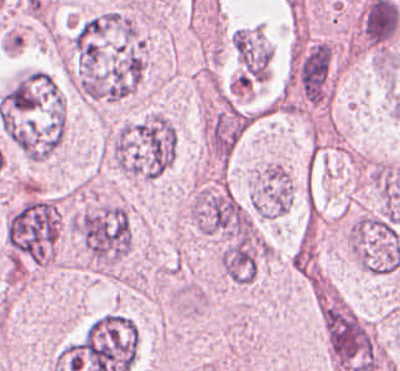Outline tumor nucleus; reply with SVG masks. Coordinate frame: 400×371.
Instances as JSON below:
<instances>
[{"mask_svg": "<svg viewBox=\"0 0 400 371\" xmlns=\"http://www.w3.org/2000/svg\"><path fill=\"white\" fill-rule=\"evenodd\" d=\"M175 129L162 113L150 112L120 124L115 136V168L139 180H152L171 165Z\"/></svg>", "mask_w": 400, "mask_h": 371, "instance_id": "2f306a5c", "label": "tumor nucleus"}, {"mask_svg": "<svg viewBox=\"0 0 400 371\" xmlns=\"http://www.w3.org/2000/svg\"><path fill=\"white\" fill-rule=\"evenodd\" d=\"M291 198V176L284 165L269 163L259 169L250 199L255 215L275 218L289 210Z\"/></svg>", "mask_w": 400, "mask_h": 371, "instance_id": "5ab6c2c4", "label": "tumor nucleus"}, {"mask_svg": "<svg viewBox=\"0 0 400 371\" xmlns=\"http://www.w3.org/2000/svg\"><path fill=\"white\" fill-rule=\"evenodd\" d=\"M73 231L95 269H109L129 253L131 231L120 205L102 204L76 216Z\"/></svg>", "mask_w": 400, "mask_h": 371, "instance_id": "8643909e", "label": "tumor nucleus"}]
</instances>
